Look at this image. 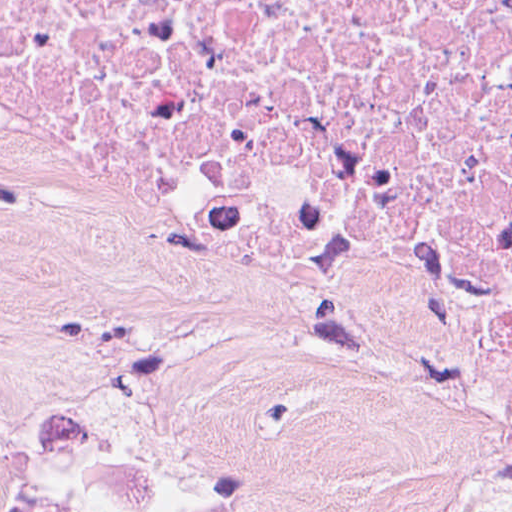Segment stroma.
<instances>
[{
    "label": "stroma",
    "mask_w": 512,
    "mask_h": 512,
    "mask_svg": "<svg viewBox=\"0 0 512 512\" xmlns=\"http://www.w3.org/2000/svg\"><path fill=\"white\" fill-rule=\"evenodd\" d=\"M0 512H512V464L109 264L0 164Z\"/></svg>",
    "instance_id": "1"
}]
</instances>
